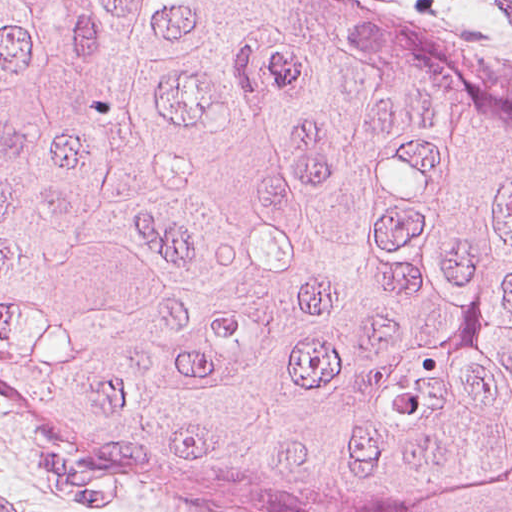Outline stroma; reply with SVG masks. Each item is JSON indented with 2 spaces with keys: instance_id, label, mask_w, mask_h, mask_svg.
Segmentation results:
<instances>
[{
  "instance_id": "35a3bbf8",
  "label": "stroma",
  "mask_w": 512,
  "mask_h": 512,
  "mask_svg": "<svg viewBox=\"0 0 512 512\" xmlns=\"http://www.w3.org/2000/svg\"><path fill=\"white\" fill-rule=\"evenodd\" d=\"M512 73V0H367ZM0 512H207L146 489L0 390Z\"/></svg>"
}]
</instances>
